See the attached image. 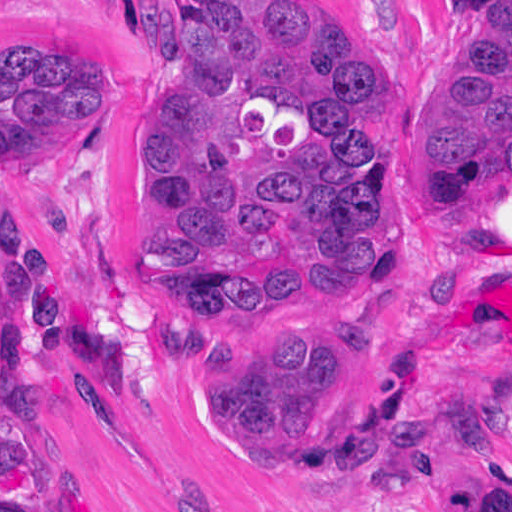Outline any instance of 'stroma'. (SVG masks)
Listing matches in <instances>:
<instances>
[{
  "label": "stroma",
  "mask_w": 512,
  "mask_h": 512,
  "mask_svg": "<svg viewBox=\"0 0 512 512\" xmlns=\"http://www.w3.org/2000/svg\"><path fill=\"white\" fill-rule=\"evenodd\" d=\"M377 73L372 146L393 144L390 251L378 283L254 299L169 319L149 304L139 256L144 152L183 63L176 0H0L1 487L32 512H453L481 465L512 463L490 419L512 387V171L443 164L427 191L420 151L442 81L512 0H304ZM72 52L115 81L98 125L1 165V55ZM59 234L137 313L164 361L152 399L28 376L1 344V248ZM337 332L316 449L346 456L421 405L452 439L421 489L349 494L209 442L189 415L194 359L216 337Z\"/></svg>",
  "instance_id": "1"
}]
</instances>
